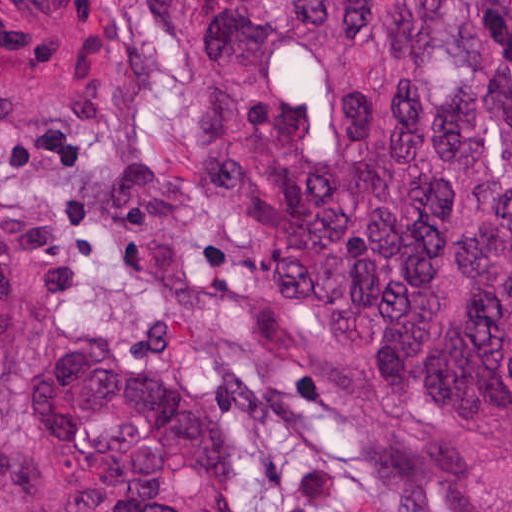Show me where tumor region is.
Masks as SVG:
<instances>
[{
	"label": "tumor region",
	"mask_w": 512,
	"mask_h": 512,
	"mask_svg": "<svg viewBox=\"0 0 512 512\" xmlns=\"http://www.w3.org/2000/svg\"><path fill=\"white\" fill-rule=\"evenodd\" d=\"M277 304L348 332L467 512H512V0H152ZM219 411L61 354L0 99V512H239Z\"/></svg>",
	"instance_id": "tumor-region-1"
}]
</instances>
